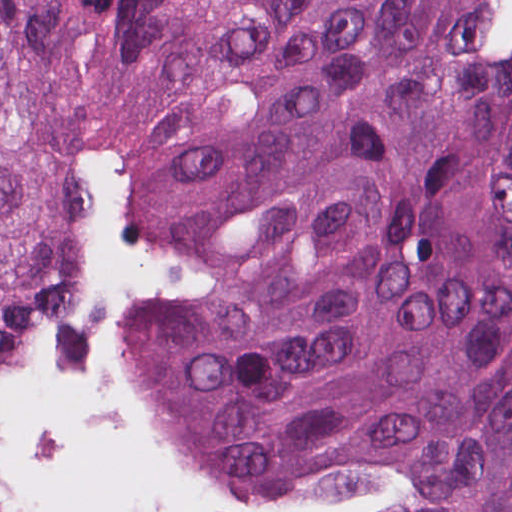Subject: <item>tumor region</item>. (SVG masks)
Wrapping results in <instances>:
<instances>
[{"mask_svg":"<svg viewBox=\"0 0 512 512\" xmlns=\"http://www.w3.org/2000/svg\"><path fill=\"white\" fill-rule=\"evenodd\" d=\"M474 0H0V359L91 286L100 151L213 270L144 334L226 494L357 459L339 512H512V54Z\"/></svg>","mask_w":512,"mask_h":512,"instance_id":"tumor-region-1","label":"tumor region"}]
</instances>
